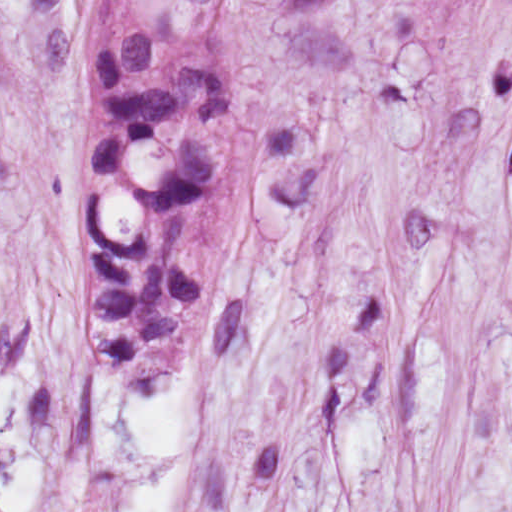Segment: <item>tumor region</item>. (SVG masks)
<instances>
[{
  "label": "tumor region",
  "mask_w": 512,
  "mask_h": 512,
  "mask_svg": "<svg viewBox=\"0 0 512 512\" xmlns=\"http://www.w3.org/2000/svg\"><path fill=\"white\" fill-rule=\"evenodd\" d=\"M242 0H104L87 104L83 313L132 395L174 380L236 231Z\"/></svg>",
  "instance_id": "obj_1"
}]
</instances>
